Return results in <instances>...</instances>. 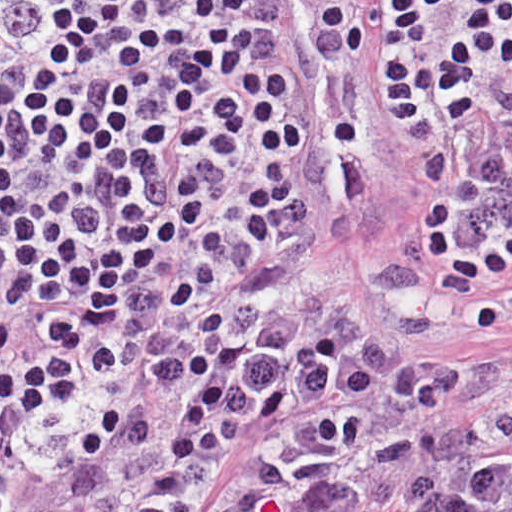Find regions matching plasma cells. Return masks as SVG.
Segmentation results:
<instances>
[{"mask_svg":"<svg viewBox=\"0 0 512 512\" xmlns=\"http://www.w3.org/2000/svg\"><path fill=\"white\" fill-rule=\"evenodd\" d=\"M320 1L405 141L396 271L355 282L358 305H338L295 365L211 390L163 435L124 426L121 478L91 477L51 512H184L245 424L317 396L359 402L256 450L226 481L219 512H512V402L445 415L472 379L392 335L512 327V149L437 229L415 210L427 157L474 150L512 123V71L486 0ZM485 97L492 117L477 132L421 145L406 136L433 122L456 126ZM171 184L174 209L190 220L221 232L259 221L241 160L210 139L187 150Z\"/></svg>","mask_w":512,"mask_h":512,"instance_id":"9512152a","label":"plasma cells"}]
</instances>
